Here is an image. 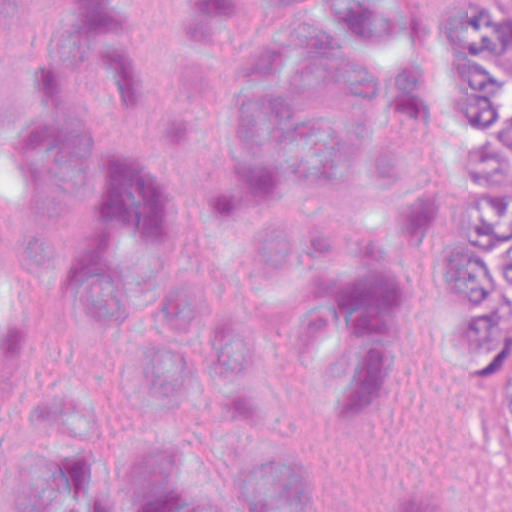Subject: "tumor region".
I'll return each mask as SVG.
<instances>
[{
    "label": "tumor region",
    "instance_id": "obj_1",
    "mask_svg": "<svg viewBox=\"0 0 512 512\" xmlns=\"http://www.w3.org/2000/svg\"><path fill=\"white\" fill-rule=\"evenodd\" d=\"M487 135L512 183V0H495V55Z\"/></svg>",
    "mask_w": 512,
    "mask_h": 512
}]
</instances>
